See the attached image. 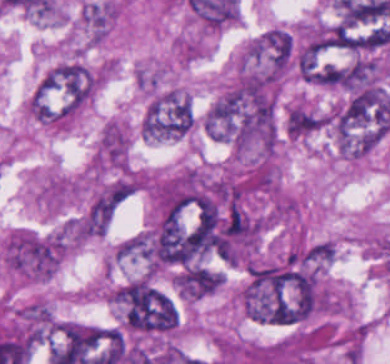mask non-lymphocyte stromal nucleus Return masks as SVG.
<instances>
[{
  "label": "non-lymphocyte stromal nucleus",
  "instance_id": "dd21d789",
  "mask_svg": "<svg viewBox=\"0 0 390 364\" xmlns=\"http://www.w3.org/2000/svg\"><path fill=\"white\" fill-rule=\"evenodd\" d=\"M64 251L61 230L13 228L0 242V261L16 279L41 283L58 269Z\"/></svg>",
  "mask_w": 390,
  "mask_h": 364
}]
</instances>
